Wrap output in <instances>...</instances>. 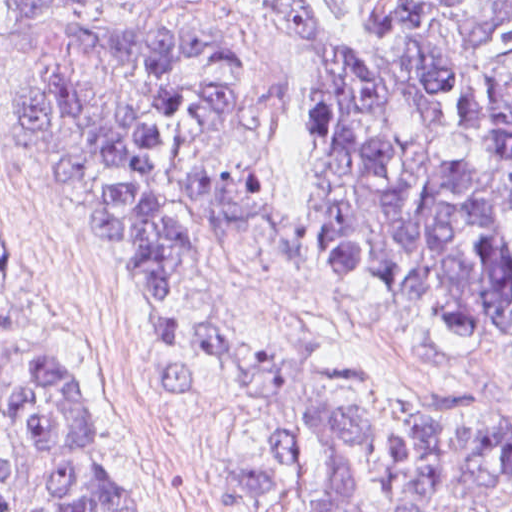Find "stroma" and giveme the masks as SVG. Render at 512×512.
Instances as JSON below:
<instances>
[{
	"label": "stroma",
	"instance_id": "1",
	"mask_svg": "<svg viewBox=\"0 0 512 512\" xmlns=\"http://www.w3.org/2000/svg\"><path fill=\"white\" fill-rule=\"evenodd\" d=\"M137 22L230 42L256 63L251 147L267 174L246 227L194 260L178 300L186 349L153 297L78 236L53 197L30 128V78L0 0V232L20 267L0 274V384L32 355L83 368L102 466L137 512H253L217 452L215 421L172 395L160 359L210 320H238L345 358L446 412L512 426V389L482 363L427 345L333 295L320 243V53L299 0H126Z\"/></svg>",
	"mask_w": 512,
	"mask_h": 512
}]
</instances>
